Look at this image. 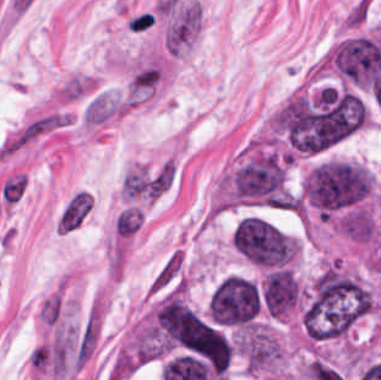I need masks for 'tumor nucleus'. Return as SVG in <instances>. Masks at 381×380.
<instances>
[{
  "mask_svg": "<svg viewBox=\"0 0 381 380\" xmlns=\"http://www.w3.org/2000/svg\"><path fill=\"white\" fill-rule=\"evenodd\" d=\"M232 243L240 254L262 268L292 265L298 244L264 217H245L232 233Z\"/></svg>",
  "mask_w": 381,
  "mask_h": 380,
  "instance_id": "1",
  "label": "tumor nucleus"
}]
</instances>
